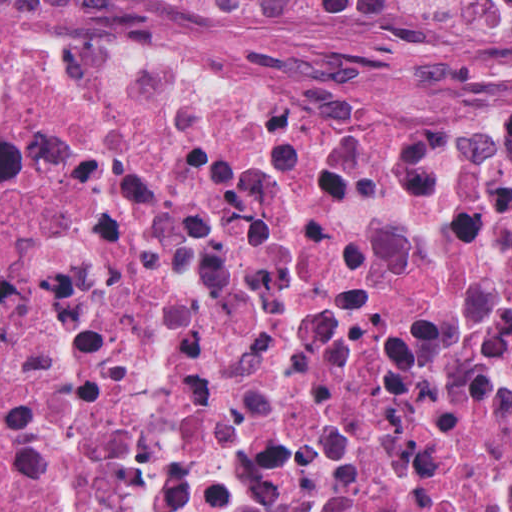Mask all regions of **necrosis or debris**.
I'll list each match as a JSON object with an SVG mask.
<instances>
[{"instance_id":"necrosis-or-debris-1","label":"necrosis or debris","mask_w":512,"mask_h":512,"mask_svg":"<svg viewBox=\"0 0 512 512\" xmlns=\"http://www.w3.org/2000/svg\"><path fill=\"white\" fill-rule=\"evenodd\" d=\"M512 69V0H0ZM0 512H512V112L0 28Z\"/></svg>"}]
</instances>
